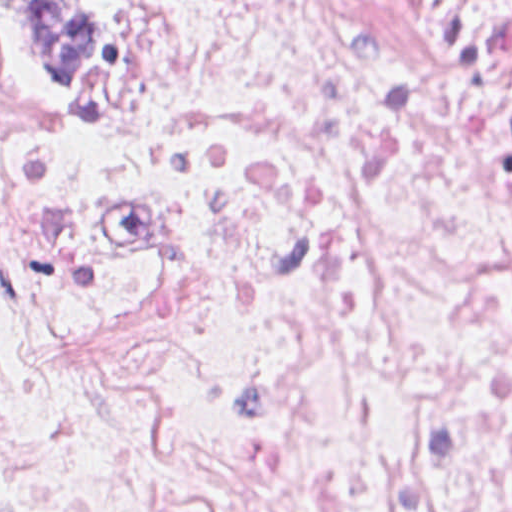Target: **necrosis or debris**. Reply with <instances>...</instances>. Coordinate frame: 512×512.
Returning a JSON list of instances; mask_svg holds the SVG:
<instances>
[{"instance_id": "1", "label": "necrosis or debris", "mask_w": 512, "mask_h": 512, "mask_svg": "<svg viewBox=\"0 0 512 512\" xmlns=\"http://www.w3.org/2000/svg\"><path fill=\"white\" fill-rule=\"evenodd\" d=\"M0 55V512H512V0H111Z\"/></svg>"}]
</instances>
